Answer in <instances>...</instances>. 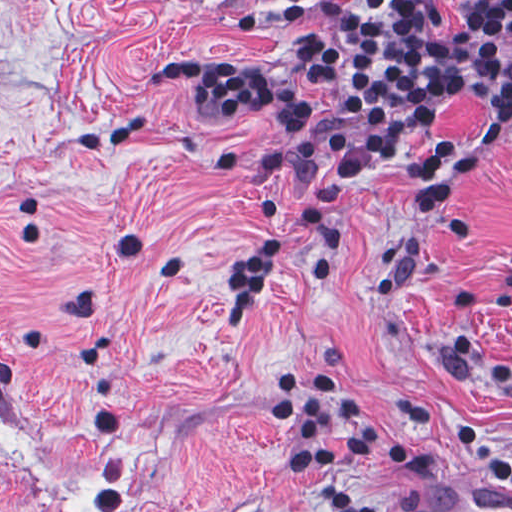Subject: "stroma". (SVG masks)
<instances>
[{
	"label": "stroma",
	"mask_w": 512,
	"mask_h": 512,
	"mask_svg": "<svg viewBox=\"0 0 512 512\" xmlns=\"http://www.w3.org/2000/svg\"><path fill=\"white\" fill-rule=\"evenodd\" d=\"M355 0H0V512H318L290 473L272 386L313 371L353 390L481 409L512 453V124L485 156V106L452 95L435 139L472 151L427 237L410 167L384 162L329 204L332 279L317 237L266 219L305 202L292 182L221 164L282 146L260 116L208 123L169 60H237L325 96L290 50ZM462 0H439L443 39ZM484 237L453 244L459 210ZM286 239L250 324H225L237 264ZM421 462L362 459L370 496L419 512H512L462 445L392 430Z\"/></svg>",
	"instance_id": "1"
}]
</instances>
